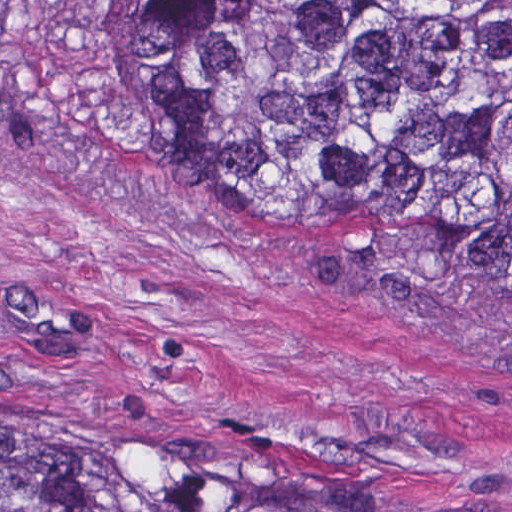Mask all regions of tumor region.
<instances>
[{
	"instance_id": "tumor-region-1",
	"label": "tumor region",
	"mask_w": 512,
	"mask_h": 512,
	"mask_svg": "<svg viewBox=\"0 0 512 512\" xmlns=\"http://www.w3.org/2000/svg\"><path fill=\"white\" fill-rule=\"evenodd\" d=\"M86 27L171 195L512 301V0H86ZM1 512L420 511L321 505L118 414L1 409Z\"/></svg>"
}]
</instances>
